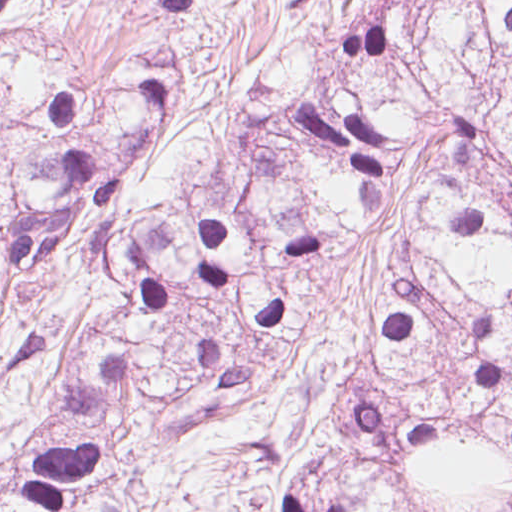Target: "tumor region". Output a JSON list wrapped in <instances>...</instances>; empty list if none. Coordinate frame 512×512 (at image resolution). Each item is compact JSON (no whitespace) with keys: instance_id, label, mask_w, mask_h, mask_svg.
I'll use <instances>...</instances> for the list:
<instances>
[{"instance_id":"obj_1","label":"tumor region","mask_w":512,"mask_h":512,"mask_svg":"<svg viewBox=\"0 0 512 512\" xmlns=\"http://www.w3.org/2000/svg\"><path fill=\"white\" fill-rule=\"evenodd\" d=\"M191 81L161 43L97 93L0 24V352L72 247L130 298L0 512H512V0H370L228 185L126 227Z\"/></svg>"}]
</instances>
